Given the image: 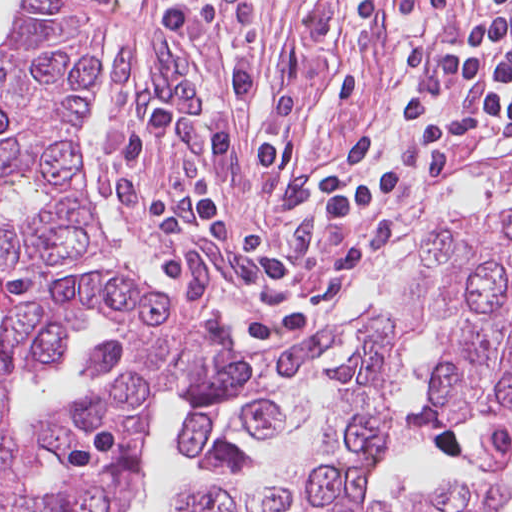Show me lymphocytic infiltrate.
Returning <instances> with one entry per match:
<instances>
[{"mask_svg": "<svg viewBox=\"0 0 512 512\" xmlns=\"http://www.w3.org/2000/svg\"><path fill=\"white\" fill-rule=\"evenodd\" d=\"M166 42L183 62L211 85L206 67V35L212 12L195 0L181 2L156 20ZM512 38V10H497L480 23L452 32L402 62L382 80ZM229 96L217 118L195 126L175 105L152 112L122 133L105 152L110 169L213 134L289 110L265 87L238 46L226 59Z\"/></svg>", "mask_w": 512, "mask_h": 512, "instance_id": "lymphocytic-infiltrate-1", "label": "lymphocytic infiltrate"}]
</instances>
